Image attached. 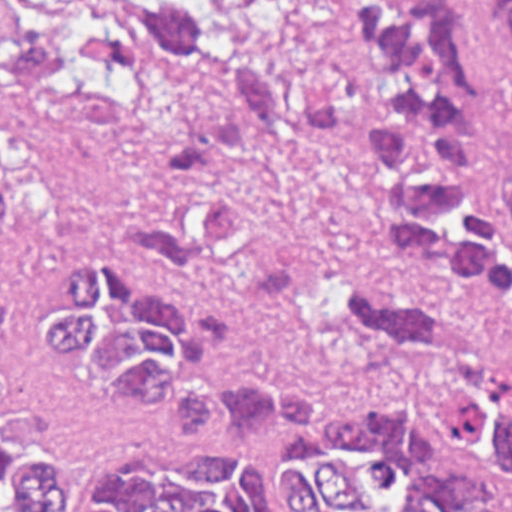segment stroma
I'll return each mask as SVG.
<instances>
[{
    "label": "stroma",
    "instance_id": "obj_1",
    "mask_svg": "<svg viewBox=\"0 0 512 512\" xmlns=\"http://www.w3.org/2000/svg\"><path fill=\"white\" fill-rule=\"evenodd\" d=\"M53 0H0V37L39 26ZM239 18L266 0H203ZM495 94L496 162L512 160V29L477 0ZM159 112H94L45 88L0 82V439L27 437L92 481L117 458L176 443L182 425L91 393L27 341L74 254H129L125 210L162 157ZM231 188L255 232L217 272L152 264L212 341L293 388L341 387L356 363L326 296L349 274H399L360 199L352 152L270 144L240 158ZM476 330L512 353V323L459 303Z\"/></svg>",
    "mask_w": 512,
    "mask_h": 512
}]
</instances>
